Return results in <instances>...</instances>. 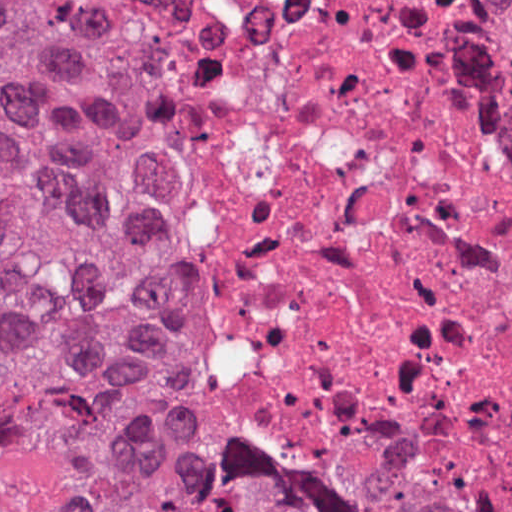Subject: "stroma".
Listing matches in <instances>:
<instances>
[{"mask_svg": "<svg viewBox=\"0 0 512 512\" xmlns=\"http://www.w3.org/2000/svg\"><path fill=\"white\" fill-rule=\"evenodd\" d=\"M0 1H32L37 10L41 15L60 25L65 30V4L67 0H0ZM494 5L498 6L497 1H512V0H488ZM178 390L187 415L198 435V437L206 443L209 447H211L214 451L220 454L230 455V456H239L251 462H254L259 465H263L266 467H270L272 469H276L283 472L295 473L291 471H286L282 469L275 468L266 463L260 462L256 459H253L248 456H244L228 445L225 441H223L217 434H215L210 428H208L202 418L200 413L198 412L196 406L194 405L192 399L184 390V388L180 385L178 379ZM300 474V473H297ZM306 475V474H305ZM511 510V509H509ZM508 511V510H506ZM504 512V511H503Z\"/></svg>", "mask_w": 512, "mask_h": 512, "instance_id": "obj_1", "label": "stroma"}]
</instances>
